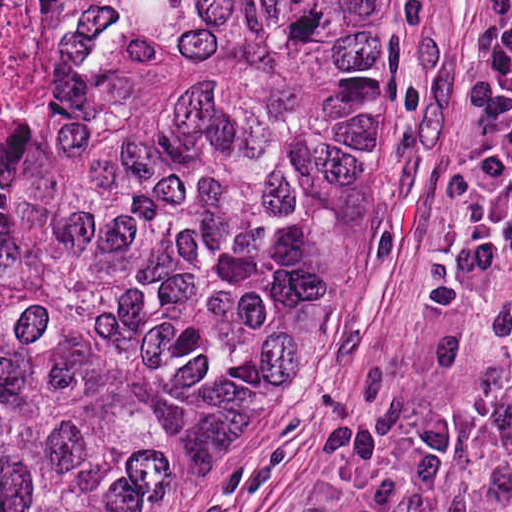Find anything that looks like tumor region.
<instances>
[{
    "label": "tumor region",
    "mask_w": 512,
    "mask_h": 512,
    "mask_svg": "<svg viewBox=\"0 0 512 512\" xmlns=\"http://www.w3.org/2000/svg\"><path fill=\"white\" fill-rule=\"evenodd\" d=\"M388 156L389 0H13L0 512H156Z\"/></svg>",
    "instance_id": "e687c5a6"
}]
</instances>
